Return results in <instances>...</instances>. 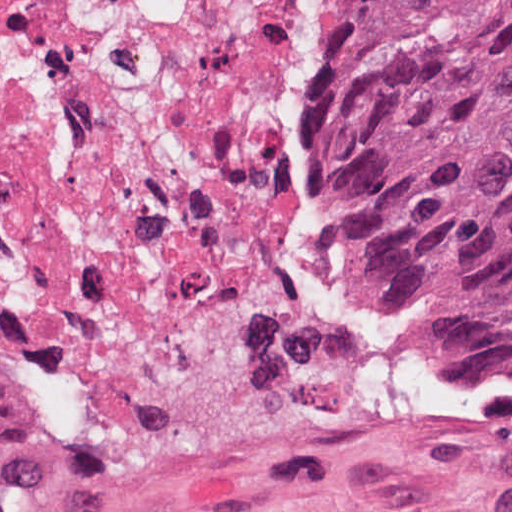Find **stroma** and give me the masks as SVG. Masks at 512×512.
Wrapping results in <instances>:
<instances>
[{
	"instance_id": "1",
	"label": "stroma",
	"mask_w": 512,
	"mask_h": 512,
	"mask_svg": "<svg viewBox=\"0 0 512 512\" xmlns=\"http://www.w3.org/2000/svg\"><path fill=\"white\" fill-rule=\"evenodd\" d=\"M371 0H339L287 94L291 273L99 430L41 415L0 512H512V357L355 243L350 106Z\"/></svg>"
}]
</instances>
